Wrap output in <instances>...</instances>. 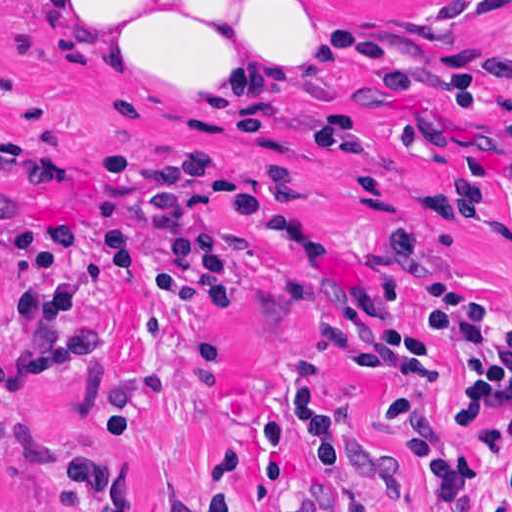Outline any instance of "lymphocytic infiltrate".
I'll list each match as a JSON object with an SVG mask.
<instances>
[{"label": "lymphocytic infiltrate", "instance_id": "obj_1", "mask_svg": "<svg viewBox=\"0 0 512 512\" xmlns=\"http://www.w3.org/2000/svg\"><path fill=\"white\" fill-rule=\"evenodd\" d=\"M314 33L311 96L345 60H363L384 85L403 95L417 88L406 47L366 28L320 16ZM512 14L497 10L482 50L444 87L445 106L483 117L500 87ZM281 138L319 155L361 157L369 136L359 116L335 108ZM272 191L218 150L177 142H110L99 153L87 196L68 219H10V303L24 320L28 360L24 377L81 373L100 360L98 318L87 303V277L73 263L79 239L107 249L118 270L166 282L204 308L237 300L229 257L232 243L267 215ZM397 267L426 286L432 304L409 329L395 320L399 294L387 283L359 286L325 321V339L348 361L368 370L401 368L436 380L435 345L459 361L455 419L489 442L464 450L438 437L404 399L381 403L383 424L416 449L439 484V512H512V321L502 318L499 293L440 266L418 233L398 229L390 242ZM294 412L322 460L338 500L355 512H380L361 477V465L340 409L313 372L294 379ZM297 452L283 421L263 435V480L278 512H314L291 484ZM74 512H139L123 468L102 458L75 456L54 465ZM248 471L228 459L203 499L180 512H245ZM20 512H40L24 492Z\"/></svg>", "mask_w": 512, "mask_h": 512}]
</instances>
